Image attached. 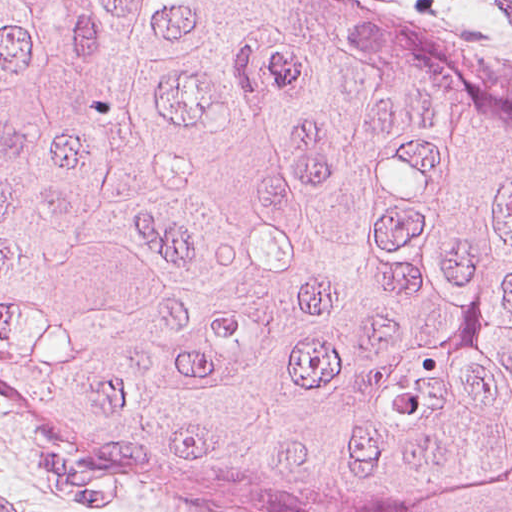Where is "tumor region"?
Wrapping results in <instances>:
<instances>
[{
  "label": "tumor region",
  "instance_id": "e687c5a6",
  "mask_svg": "<svg viewBox=\"0 0 512 512\" xmlns=\"http://www.w3.org/2000/svg\"><path fill=\"white\" fill-rule=\"evenodd\" d=\"M0 390L207 512H512V73L367 0H0Z\"/></svg>",
  "mask_w": 512,
  "mask_h": 512
}]
</instances>
